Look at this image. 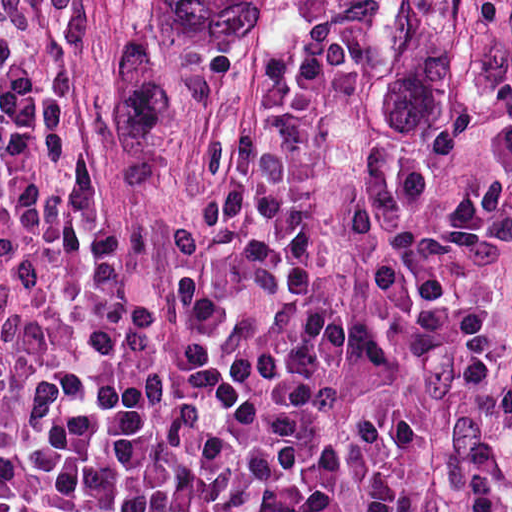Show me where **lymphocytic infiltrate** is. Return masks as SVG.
I'll return each instance as SVG.
<instances>
[{
	"label": "lymphocytic infiltrate",
	"instance_id": "f902f5d3",
	"mask_svg": "<svg viewBox=\"0 0 512 512\" xmlns=\"http://www.w3.org/2000/svg\"><path fill=\"white\" fill-rule=\"evenodd\" d=\"M92 0H0V512H424L437 345L512 208L370 195L355 0H295L175 195L100 186ZM473 512H512V290Z\"/></svg>",
	"mask_w": 512,
	"mask_h": 512
}]
</instances>
